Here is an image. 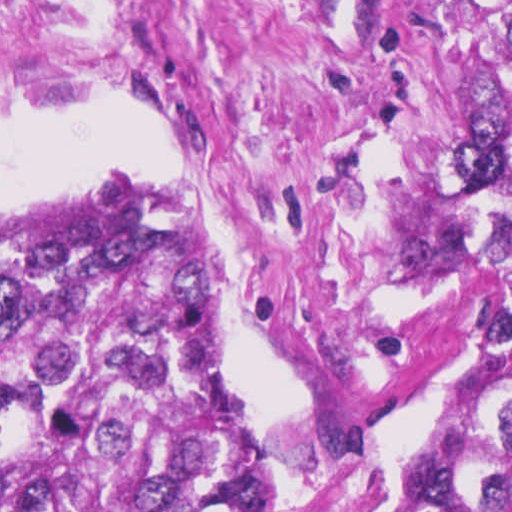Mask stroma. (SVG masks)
<instances>
[{
    "label": "stroma",
    "instance_id": "35a3bbf8",
    "mask_svg": "<svg viewBox=\"0 0 512 512\" xmlns=\"http://www.w3.org/2000/svg\"><path fill=\"white\" fill-rule=\"evenodd\" d=\"M512 0H0V104L142 107L184 181L279 512H419L458 419L467 81ZM41 211V210H40Z\"/></svg>",
    "mask_w": 512,
    "mask_h": 512
}]
</instances>
